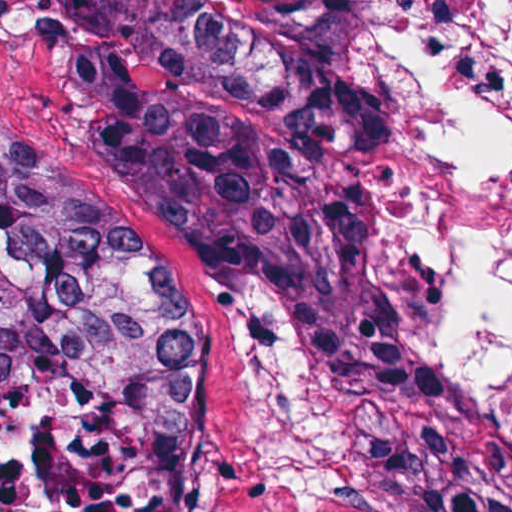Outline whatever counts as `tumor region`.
<instances>
[{
	"mask_svg": "<svg viewBox=\"0 0 512 512\" xmlns=\"http://www.w3.org/2000/svg\"><path fill=\"white\" fill-rule=\"evenodd\" d=\"M81 50L95 161L194 242L264 353L267 425L305 476L410 512H512V407L410 241L373 58L381 0H48ZM58 337L139 346L178 411L194 320L137 230L0 132V380Z\"/></svg>",
	"mask_w": 512,
	"mask_h": 512,
	"instance_id": "1",
	"label": "tumor region"
}]
</instances>
